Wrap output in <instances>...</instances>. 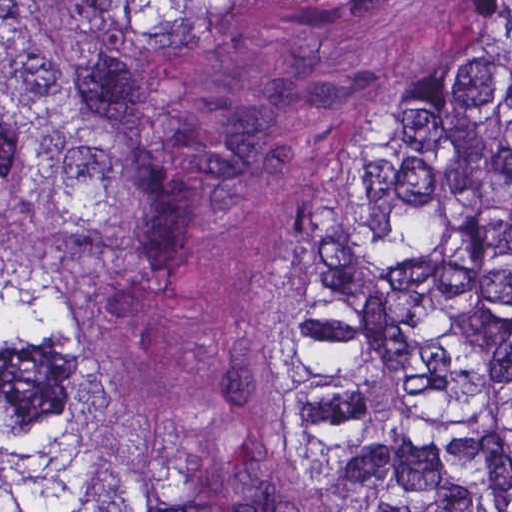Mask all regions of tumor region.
<instances>
[{
  "mask_svg": "<svg viewBox=\"0 0 512 512\" xmlns=\"http://www.w3.org/2000/svg\"><path fill=\"white\" fill-rule=\"evenodd\" d=\"M291 3L0 1V512H141L77 437V376L196 262L133 34ZM294 327L300 422L359 512H512V1L401 94Z\"/></svg>",
  "mask_w": 512,
  "mask_h": 512,
  "instance_id": "obj_1",
  "label": "tumor region"
}]
</instances>
